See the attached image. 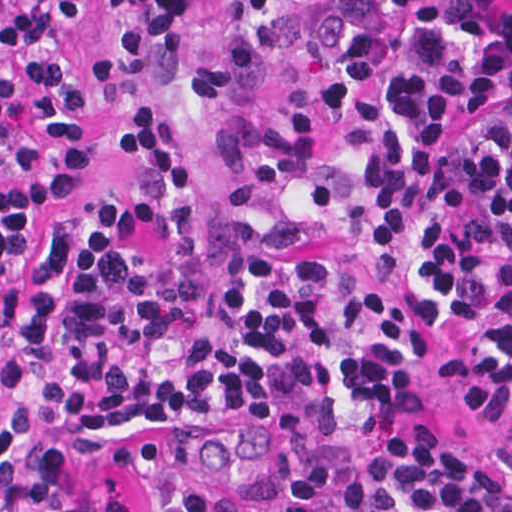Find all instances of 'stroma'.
Wrapping results in <instances>:
<instances>
[{"instance_id":"1","label":"stroma","mask_w":512,"mask_h":512,"mask_svg":"<svg viewBox=\"0 0 512 512\" xmlns=\"http://www.w3.org/2000/svg\"><path fill=\"white\" fill-rule=\"evenodd\" d=\"M338 0H276L259 17L236 14L238 0H194L181 21L154 17L114 0H83V20L71 38L81 65L110 57L128 40L174 48L187 63L221 57L256 36L273 42L245 76L227 89L159 87L129 90L94 107L75 127L38 128L33 158L0 185L46 171L62 151L84 153L87 169L29 233L39 248L51 224L94 197L118 201L143 215L123 165L127 123L162 119L196 174V227L210 260L222 257L218 223L224 185L243 121L264 126L296 113L321 91L317 39ZM472 351L460 340L426 344L423 377L390 415L362 427L323 433L310 447L323 455L316 486L296 489L279 478L271 427L255 414H214L186 424H162L125 440L118 455L97 467L59 469L25 496L0 487V512H63L101 500L121 512H149L146 480L169 468L185 471L207 495L244 512H350L353 479L391 455L424 447L436 431H456L485 453L486 424L477 400L461 392L454 374Z\"/></svg>"}]
</instances>
